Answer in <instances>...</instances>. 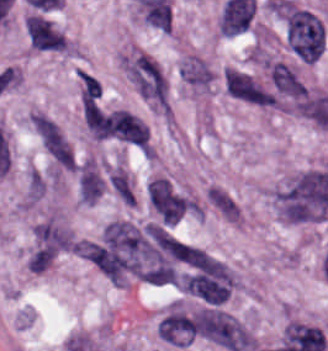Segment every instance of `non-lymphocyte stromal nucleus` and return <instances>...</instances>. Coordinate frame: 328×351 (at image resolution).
I'll return each mask as SVG.
<instances>
[{
	"label": "non-lymphocyte stromal nucleus",
	"instance_id": "1",
	"mask_svg": "<svg viewBox=\"0 0 328 351\" xmlns=\"http://www.w3.org/2000/svg\"><path fill=\"white\" fill-rule=\"evenodd\" d=\"M282 26L286 46L300 62H313L324 47L322 19L308 8L283 0Z\"/></svg>",
	"mask_w": 328,
	"mask_h": 351
},
{
	"label": "non-lymphocyte stromal nucleus",
	"instance_id": "2",
	"mask_svg": "<svg viewBox=\"0 0 328 351\" xmlns=\"http://www.w3.org/2000/svg\"><path fill=\"white\" fill-rule=\"evenodd\" d=\"M122 68L137 95L164 110L165 82L154 60L144 52H137L122 58Z\"/></svg>",
	"mask_w": 328,
	"mask_h": 351
},
{
	"label": "non-lymphocyte stromal nucleus",
	"instance_id": "3",
	"mask_svg": "<svg viewBox=\"0 0 328 351\" xmlns=\"http://www.w3.org/2000/svg\"><path fill=\"white\" fill-rule=\"evenodd\" d=\"M92 134L98 138L146 146L147 126L135 115L116 109L101 114L94 120Z\"/></svg>",
	"mask_w": 328,
	"mask_h": 351
},
{
	"label": "non-lymphocyte stromal nucleus",
	"instance_id": "4",
	"mask_svg": "<svg viewBox=\"0 0 328 351\" xmlns=\"http://www.w3.org/2000/svg\"><path fill=\"white\" fill-rule=\"evenodd\" d=\"M225 91L232 98L258 105L273 104L270 92L250 74L226 68L223 72Z\"/></svg>",
	"mask_w": 328,
	"mask_h": 351
},
{
	"label": "non-lymphocyte stromal nucleus",
	"instance_id": "5",
	"mask_svg": "<svg viewBox=\"0 0 328 351\" xmlns=\"http://www.w3.org/2000/svg\"><path fill=\"white\" fill-rule=\"evenodd\" d=\"M33 128L46 152L63 167L73 168L74 154L60 127L38 114Z\"/></svg>",
	"mask_w": 328,
	"mask_h": 351
},
{
	"label": "non-lymphocyte stromal nucleus",
	"instance_id": "6",
	"mask_svg": "<svg viewBox=\"0 0 328 351\" xmlns=\"http://www.w3.org/2000/svg\"><path fill=\"white\" fill-rule=\"evenodd\" d=\"M27 39L37 51H63V34L43 15L32 14L26 22Z\"/></svg>",
	"mask_w": 328,
	"mask_h": 351
},
{
	"label": "non-lymphocyte stromal nucleus",
	"instance_id": "7",
	"mask_svg": "<svg viewBox=\"0 0 328 351\" xmlns=\"http://www.w3.org/2000/svg\"><path fill=\"white\" fill-rule=\"evenodd\" d=\"M267 71L273 93L295 100L305 96L300 77L286 62L269 61Z\"/></svg>",
	"mask_w": 328,
	"mask_h": 351
},
{
	"label": "non-lymphocyte stromal nucleus",
	"instance_id": "8",
	"mask_svg": "<svg viewBox=\"0 0 328 351\" xmlns=\"http://www.w3.org/2000/svg\"><path fill=\"white\" fill-rule=\"evenodd\" d=\"M74 247L72 236L50 220H43L33 234V249L57 254L71 251Z\"/></svg>",
	"mask_w": 328,
	"mask_h": 351
},
{
	"label": "non-lymphocyte stromal nucleus",
	"instance_id": "9",
	"mask_svg": "<svg viewBox=\"0 0 328 351\" xmlns=\"http://www.w3.org/2000/svg\"><path fill=\"white\" fill-rule=\"evenodd\" d=\"M158 334L168 343L190 344L194 336V321L175 311L158 324Z\"/></svg>",
	"mask_w": 328,
	"mask_h": 351
},
{
	"label": "non-lymphocyte stromal nucleus",
	"instance_id": "10",
	"mask_svg": "<svg viewBox=\"0 0 328 351\" xmlns=\"http://www.w3.org/2000/svg\"><path fill=\"white\" fill-rule=\"evenodd\" d=\"M78 194L84 203H92L103 190V180L98 168L88 161H80L75 175Z\"/></svg>",
	"mask_w": 328,
	"mask_h": 351
},
{
	"label": "non-lymphocyte stromal nucleus",
	"instance_id": "11",
	"mask_svg": "<svg viewBox=\"0 0 328 351\" xmlns=\"http://www.w3.org/2000/svg\"><path fill=\"white\" fill-rule=\"evenodd\" d=\"M146 192L153 209L163 214H175V195L166 178L148 181Z\"/></svg>",
	"mask_w": 328,
	"mask_h": 351
},
{
	"label": "non-lymphocyte stromal nucleus",
	"instance_id": "12",
	"mask_svg": "<svg viewBox=\"0 0 328 351\" xmlns=\"http://www.w3.org/2000/svg\"><path fill=\"white\" fill-rule=\"evenodd\" d=\"M213 209L227 222L238 224L239 206L236 201L221 187H207L204 194Z\"/></svg>",
	"mask_w": 328,
	"mask_h": 351
},
{
	"label": "non-lymphocyte stromal nucleus",
	"instance_id": "13",
	"mask_svg": "<svg viewBox=\"0 0 328 351\" xmlns=\"http://www.w3.org/2000/svg\"><path fill=\"white\" fill-rule=\"evenodd\" d=\"M181 80L195 87H208L212 73L204 61L197 57H189L180 66Z\"/></svg>",
	"mask_w": 328,
	"mask_h": 351
},
{
	"label": "non-lymphocyte stromal nucleus",
	"instance_id": "14",
	"mask_svg": "<svg viewBox=\"0 0 328 351\" xmlns=\"http://www.w3.org/2000/svg\"><path fill=\"white\" fill-rule=\"evenodd\" d=\"M107 183L116 198L125 205H132L133 192L125 174L119 168H112L107 176Z\"/></svg>",
	"mask_w": 328,
	"mask_h": 351
},
{
	"label": "non-lymphocyte stromal nucleus",
	"instance_id": "15",
	"mask_svg": "<svg viewBox=\"0 0 328 351\" xmlns=\"http://www.w3.org/2000/svg\"><path fill=\"white\" fill-rule=\"evenodd\" d=\"M75 75L81 103L86 106L100 95L101 87L92 76L78 70Z\"/></svg>",
	"mask_w": 328,
	"mask_h": 351
},
{
	"label": "non-lymphocyte stromal nucleus",
	"instance_id": "16",
	"mask_svg": "<svg viewBox=\"0 0 328 351\" xmlns=\"http://www.w3.org/2000/svg\"><path fill=\"white\" fill-rule=\"evenodd\" d=\"M54 257L53 246L37 245L26 260L27 268L42 272Z\"/></svg>",
	"mask_w": 328,
	"mask_h": 351
}]
</instances>
